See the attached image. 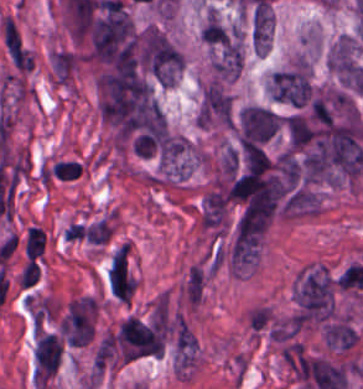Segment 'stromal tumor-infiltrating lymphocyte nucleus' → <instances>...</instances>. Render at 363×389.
<instances>
[{
	"label": "stromal tumor-infiltrating lymphocyte nucleus",
	"instance_id": "stromal-tumor-infiltrating-lymphocyte-nucleus-1",
	"mask_svg": "<svg viewBox=\"0 0 363 389\" xmlns=\"http://www.w3.org/2000/svg\"><path fill=\"white\" fill-rule=\"evenodd\" d=\"M46 236L43 229L30 226L22 237V252L25 260H37L44 247Z\"/></svg>",
	"mask_w": 363,
	"mask_h": 389
}]
</instances>
